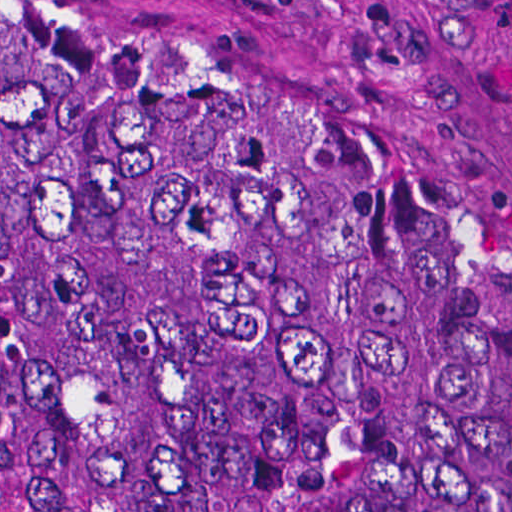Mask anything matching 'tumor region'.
Here are the masks:
<instances>
[{"label": "tumor region", "mask_w": 512, "mask_h": 512, "mask_svg": "<svg viewBox=\"0 0 512 512\" xmlns=\"http://www.w3.org/2000/svg\"><path fill=\"white\" fill-rule=\"evenodd\" d=\"M19 512H512V319L208 50L0 0Z\"/></svg>", "instance_id": "e687c5a6"}]
</instances>
